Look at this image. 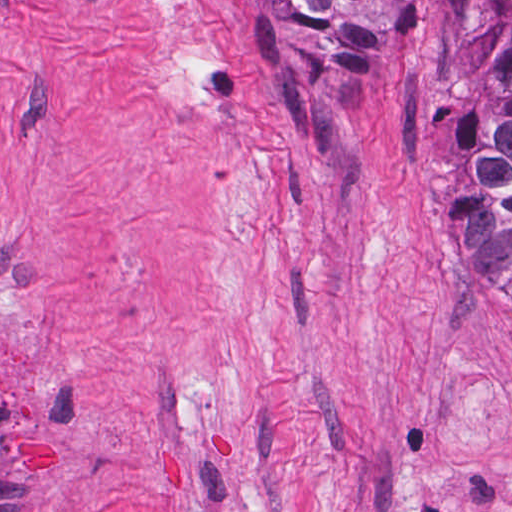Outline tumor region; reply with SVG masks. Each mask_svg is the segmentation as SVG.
Returning a JSON list of instances; mask_svg holds the SVG:
<instances>
[{"instance_id":"e687c5a6","label":"tumor region","mask_w":512,"mask_h":512,"mask_svg":"<svg viewBox=\"0 0 512 512\" xmlns=\"http://www.w3.org/2000/svg\"><path fill=\"white\" fill-rule=\"evenodd\" d=\"M299 20L357 11L366 0H270ZM447 16L468 76L467 102L436 221L467 261L512 288V0H432Z\"/></svg>"}]
</instances>
